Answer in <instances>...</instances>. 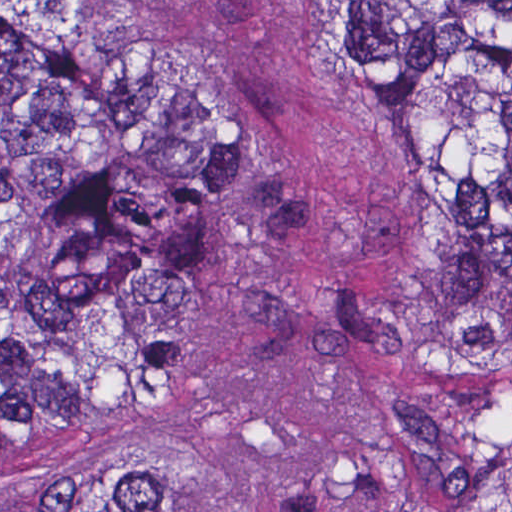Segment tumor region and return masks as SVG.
<instances>
[{
	"instance_id": "obj_1",
	"label": "tumor region",
	"mask_w": 512,
	"mask_h": 512,
	"mask_svg": "<svg viewBox=\"0 0 512 512\" xmlns=\"http://www.w3.org/2000/svg\"><path fill=\"white\" fill-rule=\"evenodd\" d=\"M355 85L422 175L427 293L385 375L426 512H512V1H343ZM295 214L285 145L166 49L0 1V512H174L150 418L172 316Z\"/></svg>"
}]
</instances>
